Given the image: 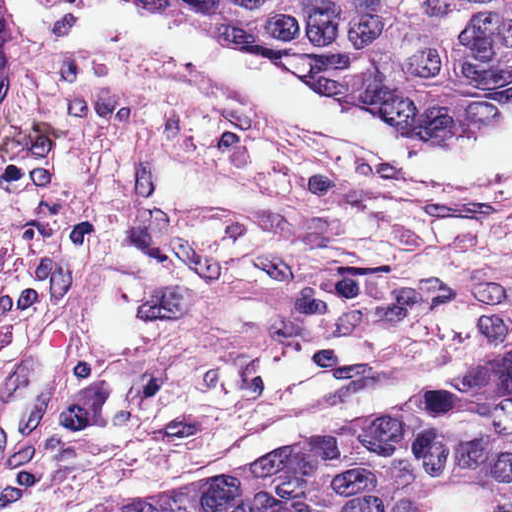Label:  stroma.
Masks as SVG:
<instances>
[{
	"instance_id": "stroma-1",
	"label": "stroma",
	"mask_w": 512,
	"mask_h": 512,
	"mask_svg": "<svg viewBox=\"0 0 512 512\" xmlns=\"http://www.w3.org/2000/svg\"><path fill=\"white\" fill-rule=\"evenodd\" d=\"M170 75L332 438L512 351V191L388 179Z\"/></svg>"
}]
</instances>
